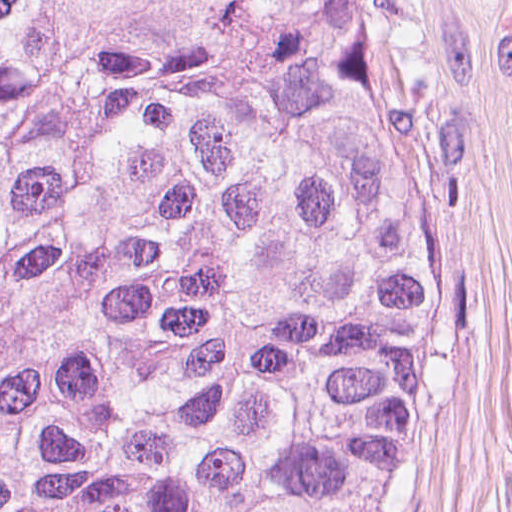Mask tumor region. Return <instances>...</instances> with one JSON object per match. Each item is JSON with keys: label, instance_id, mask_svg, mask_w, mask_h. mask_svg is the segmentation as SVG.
I'll use <instances>...</instances> for the list:
<instances>
[{"label": "tumor region", "instance_id": "obj_1", "mask_svg": "<svg viewBox=\"0 0 512 512\" xmlns=\"http://www.w3.org/2000/svg\"><path fill=\"white\" fill-rule=\"evenodd\" d=\"M444 263L407 0H0V512H372Z\"/></svg>", "mask_w": 512, "mask_h": 512}]
</instances>
